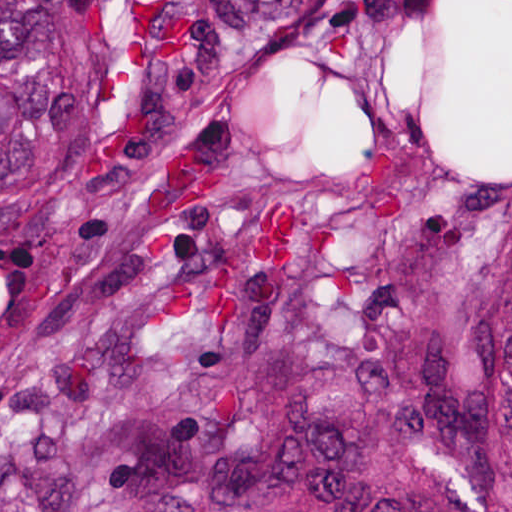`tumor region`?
Instances as JSON below:
<instances>
[{
	"label": "tumor region",
	"mask_w": 512,
	"mask_h": 512,
	"mask_svg": "<svg viewBox=\"0 0 512 512\" xmlns=\"http://www.w3.org/2000/svg\"><path fill=\"white\" fill-rule=\"evenodd\" d=\"M0 512H512V0H0Z\"/></svg>",
	"instance_id": "1"
}]
</instances>
